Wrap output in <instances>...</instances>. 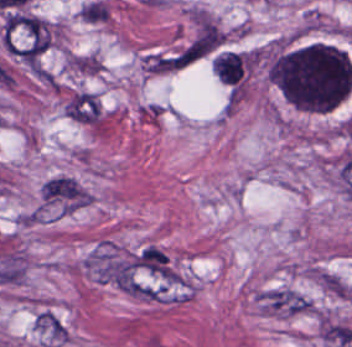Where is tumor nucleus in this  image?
<instances>
[{
	"mask_svg": "<svg viewBox=\"0 0 352 347\" xmlns=\"http://www.w3.org/2000/svg\"><path fill=\"white\" fill-rule=\"evenodd\" d=\"M347 57L320 43L281 53L273 62V82L296 109L328 110L347 90L351 78Z\"/></svg>",
	"mask_w": 352,
	"mask_h": 347,
	"instance_id": "2f306a5c",
	"label": "tumor nucleus"
}]
</instances>
